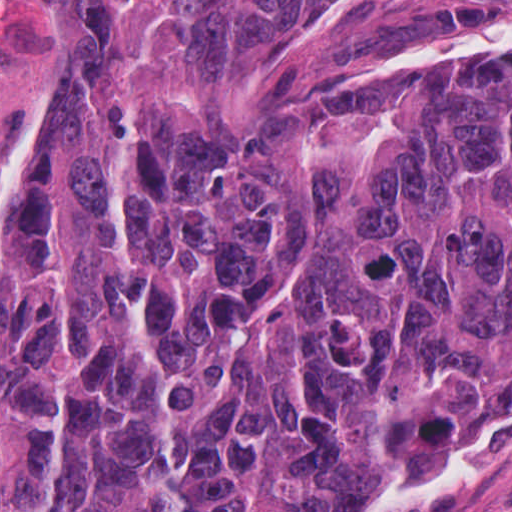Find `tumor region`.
I'll use <instances>...</instances> for the list:
<instances>
[{
	"label": "tumor region",
	"instance_id": "obj_1",
	"mask_svg": "<svg viewBox=\"0 0 512 512\" xmlns=\"http://www.w3.org/2000/svg\"><path fill=\"white\" fill-rule=\"evenodd\" d=\"M510 433L512 0L67 1L0 512H348Z\"/></svg>",
	"mask_w": 512,
	"mask_h": 512
}]
</instances>
